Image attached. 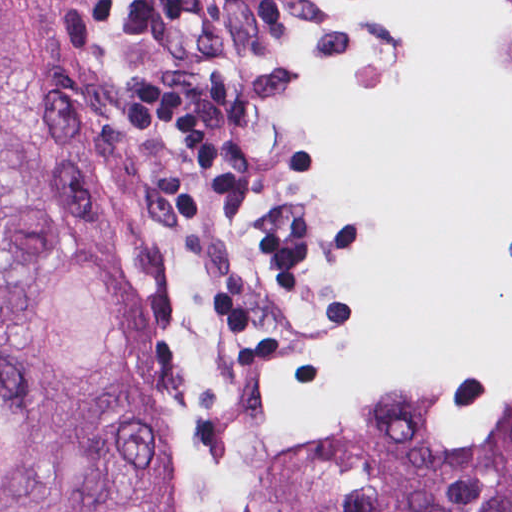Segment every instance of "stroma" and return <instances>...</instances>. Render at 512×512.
<instances>
[{
  "instance_id": "35a3bbf8",
  "label": "stroma",
  "mask_w": 512,
  "mask_h": 512,
  "mask_svg": "<svg viewBox=\"0 0 512 512\" xmlns=\"http://www.w3.org/2000/svg\"><path fill=\"white\" fill-rule=\"evenodd\" d=\"M381 235L382 222L376 217L374 248ZM510 254L512 257V246ZM422 377L438 390L449 440L464 449L483 452L505 443L512 428V391L499 387L490 365L452 375L450 360L426 361L412 370L341 391L323 421L343 415L402 382ZM185 504L187 512H193L186 500Z\"/></svg>"
}]
</instances>
